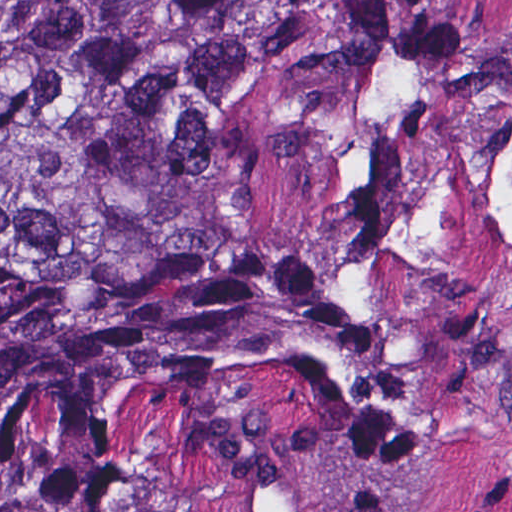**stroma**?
I'll use <instances>...</instances> for the list:
<instances>
[{
	"label": "stroma",
	"mask_w": 512,
	"mask_h": 512,
	"mask_svg": "<svg viewBox=\"0 0 512 512\" xmlns=\"http://www.w3.org/2000/svg\"><path fill=\"white\" fill-rule=\"evenodd\" d=\"M317 13L401 8L478 51L512 50V0H300ZM194 512H512V358L495 396L429 455L374 470L268 471Z\"/></svg>",
	"instance_id": "1"
}]
</instances>
